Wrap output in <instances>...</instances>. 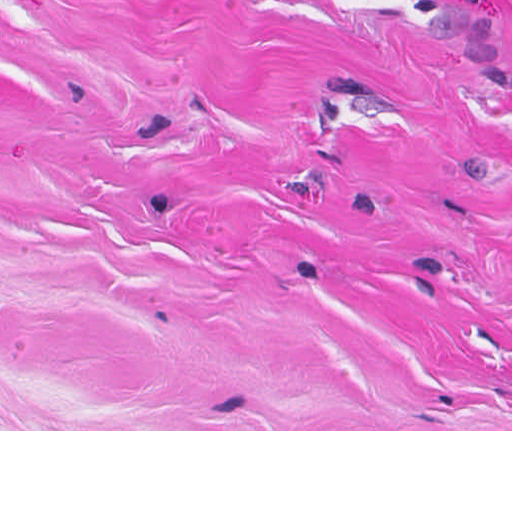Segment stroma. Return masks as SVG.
Instances as JSON below:
<instances>
[{
    "label": "stroma",
    "mask_w": 512,
    "mask_h": 512,
    "mask_svg": "<svg viewBox=\"0 0 512 512\" xmlns=\"http://www.w3.org/2000/svg\"><path fill=\"white\" fill-rule=\"evenodd\" d=\"M0 431H512V0H0Z\"/></svg>",
    "instance_id": "35a3bbf8"
}]
</instances>
